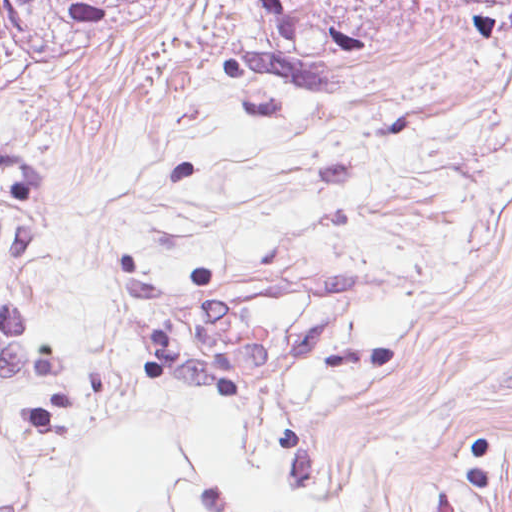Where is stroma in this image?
Returning a JSON list of instances; mask_svg holds the SVG:
<instances>
[{
    "label": "stroma",
    "mask_w": 512,
    "mask_h": 512,
    "mask_svg": "<svg viewBox=\"0 0 512 512\" xmlns=\"http://www.w3.org/2000/svg\"><path fill=\"white\" fill-rule=\"evenodd\" d=\"M110 52L82 63L0 54V151L18 152L41 170L59 211Z\"/></svg>",
    "instance_id": "1"
}]
</instances>
